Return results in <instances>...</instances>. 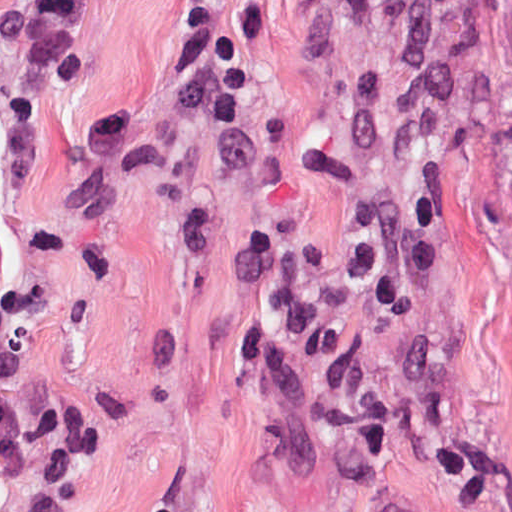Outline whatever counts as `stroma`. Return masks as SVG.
<instances>
[{"label": "stroma", "instance_id": "1", "mask_svg": "<svg viewBox=\"0 0 512 512\" xmlns=\"http://www.w3.org/2000/svg\"><path fill=\"white\" fill-rule=\"evenodd\" d=\"M179 1L88 0L67 85L0 46V291L42 296L3 384L100 406L95 461L54 482L0 463V512H512V0H223L230 131L171 107ZM115 106L134 148L92 157ZM420 192L435 278L338 318L399 421L388 463L352 464L309 373L236 359L277 287L233 265L270 230L319 284L365 208Z\"/></svg>", "mask_w": 512, "mask_h": 512}]
</instances>
